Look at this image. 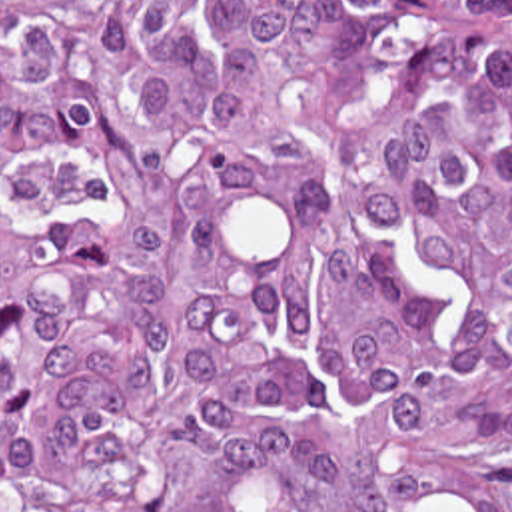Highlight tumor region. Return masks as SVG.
<instances>
[{
	"instance_id": "1",
	"label": "tumor region",
	"mask_w": 512,
	"mask_h": 512,
	"mask_svg": "<svg viewBox=\"0 0 512 512\" xmlns=\"http://www.w3.org/2000/svg\"><path fill=\"white\" fill-rule=\"evenodd\" d=\"M512 0L0 10V509L512 512Z\"/></svg>"
}]
</instances>
